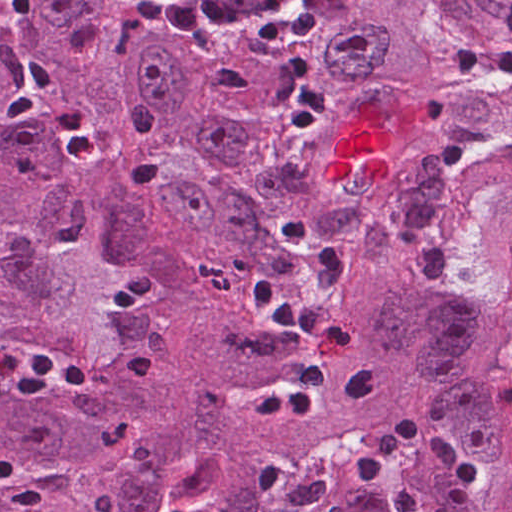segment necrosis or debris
Segmentation results:
<instances>
[{"label": "necrosis or debris", "mask_w": 512, "mask_h": 512, "mask_svg": "<svg viewBox=\"0 0 512 512\" xmlns=\"http://www.w3.org/2000/svg\"><path fill=\"white\" fill-rule=\"evenodd\" d=\"M163 42L207 50L234 39L296 37L324 26L327 0H120Z\"/></svg>", "instance_id": "4bbe7bcc"}]
</instances>
